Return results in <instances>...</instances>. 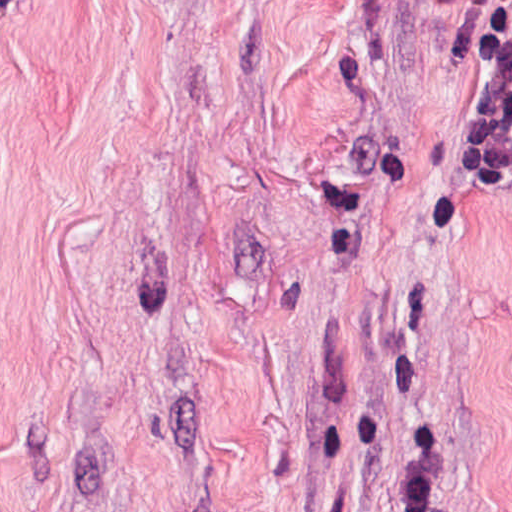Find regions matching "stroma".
I'll list each match as a JSON object with an SVG mask.
<instances>
[{
	"label": "stroma",
	"instance_id": "1",
	"mask_svg": "<svg viewBox=\"0 0 512 512\" xmlns=\"http://www.w3.org/2000/svg\"><path fill=\"white\" fill-rule=\"evenodd\" d=\"M494 0H0V512H512Z\"/></svg>",
	"mask_w": 512,
	"mask_h": 512
}]
</instances>
